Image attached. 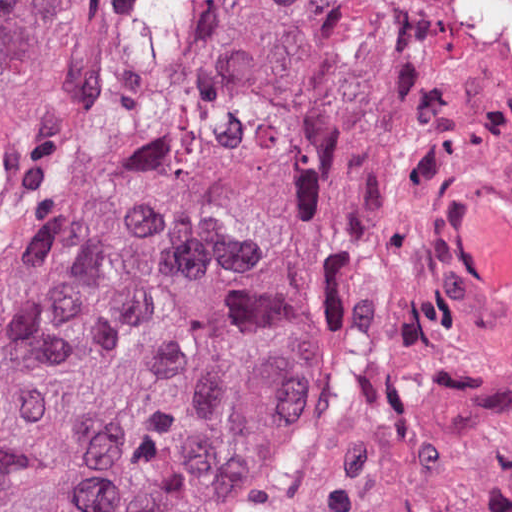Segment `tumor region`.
<instances>
[{
  "label": "tumor region",
  "instance_id": "tumor-region-1",
  "mask_svg": "<svg viewBox=\"0 0 512 512\" xmlns=\"http://www.w3.org/2000/svg\"><path fill=\"white\" fill-rule=\"evenodd\" d=\"M44 0H0V96ZM135 158L70 226L0 358V512H51L216 342L265 229L253 170L187 148Z\"/></svg>",
  "mask_w": 512,
  "mask_h": 512
}]
</instances>
